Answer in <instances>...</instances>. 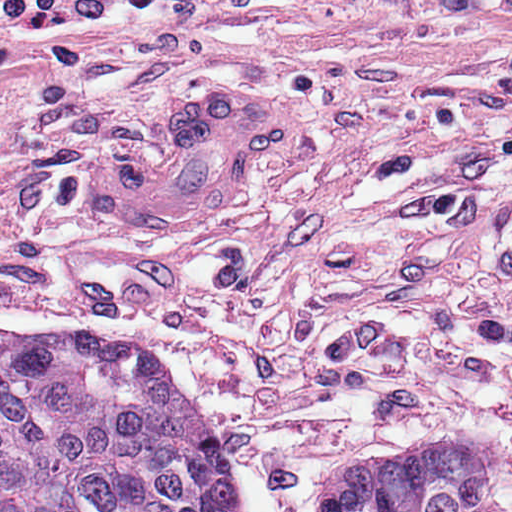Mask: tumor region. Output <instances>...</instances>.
<instances>
[{"instance_id":"tumor-region-1","label":"tumor region","mask_w":512,"mask_h":512,"mask_svg":"<svg viewBox=\"0 0 512 512\" xmlns=\"http://www.w3.org/2000/svg\"><path fill=\"white\" fill-rule=\"evenodd\" d=\"M0 512H251L155 348L0 329ZM319 512H504L486 458L389 447L328 479Z\"/></svg>"}]
</instances>
